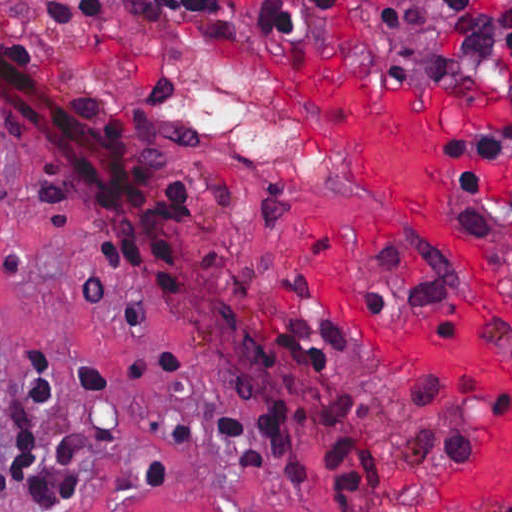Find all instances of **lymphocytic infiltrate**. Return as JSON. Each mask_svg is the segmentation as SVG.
Segmentation results:
<instances>
[{
    "label": "lymphocytic infiltrate",
    "instance_id": "1",
    "mask_svg": "<svg viewBox=\"0 0 512 512\" xmlns=\"http://www.w3.org/2000/svg\"><path fill=\"white\" fill-rule=\"evenodd\" d=\"M0 16L33 22L184 17L270 38L318 35L373 46L421 79L435 74L492 89L496 105L467 116L446 137L451 185L464 216L476 228L486 185L498 165L512 159V39L502 72L467 75L439 47L402 41L388 0H50L39 18L18 15L0 1ZM0 130L16 136L27 153L29 186L42 205L61 204L74 195L84 199L87 245L104 269L142 279L161 293L179 294L180 277L203 238L202 206L182 181L157 183L141 199L133 220L121 223L93 211L51 146L1 102ZM11 196L0 166V204L10 203ZM509 206L512 215V197ZM110 269H129L140 277ZM273 334L275 351L285 352L312 371H330L349 348L341 327L326 318H287ZM75 378L85 401L91 394L112 393L118 375L110 366L84 360L75 364ZM62 393L61 362L44 349H31L26 398L19 412L27 444L12 451L11 465L0 471V494L16 489L35 505H62L80 491L85 459L113 442L112 431L88 423L85 430L63 427L62 437L51 446L35 444L21 420L22 409L51 411ZM223 430L242 458L240 471L274 464L291 480H313L296 449L291 415L284 404L270 413L233 414ZM324 455L345 489L380 493L377 436L366 443L332 438L324 445Z\"/></svg>",
    "mask_w": 512,
    "mask_h": 512
}]
</instances>
